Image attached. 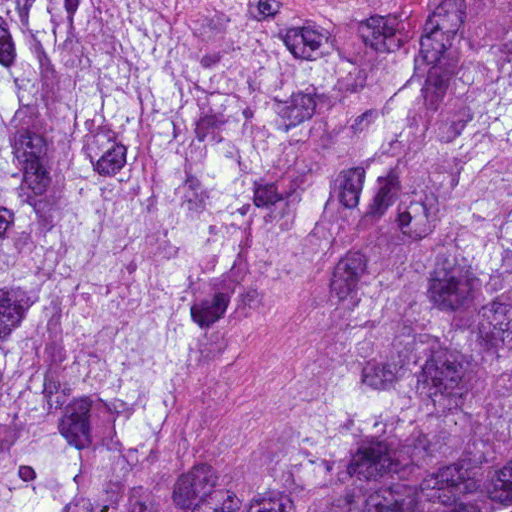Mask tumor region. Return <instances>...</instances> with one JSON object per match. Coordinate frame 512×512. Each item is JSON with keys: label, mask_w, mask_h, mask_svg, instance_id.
Returning a JSON list of instances; mask_svg holds the SVG:
<instances>
[{"label": "tumor region", "mask_w": 512, "mask_h": 512, "mask_svg": "<svg viewBox=\"0 0 512 512\" xmlns=\"http://www.w3.org/2000/svg\"><path fill=\"white\" fill-rule=\"evenodd\" d=\"M334 238L265 442L156 459ZM0 512H512V0H0Z\"/></svg>", "instance_id": "e687c5a6"}]
</instances>
